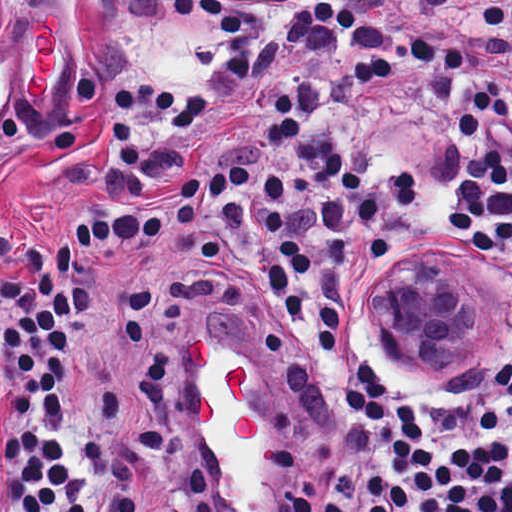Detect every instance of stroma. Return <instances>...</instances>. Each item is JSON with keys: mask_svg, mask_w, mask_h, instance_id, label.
Wrapping results in <instances>:
<instances>
[{"mask_svg": "<svg viewBox=\"0 0 512 512\" xmlns=\"http://www.w3.org/2000/svg\"><path fill=\"white\" fill-rule=\"evenodd\" d=\"M190 0H0V270L28 235H65L101 198L115 81L142 78L181 30ZM63 19L62 62L39 101L23 93L26 21ZM437 264L456 269L448 256ZM184 430L208 476L212 512H286L265 427V387L238 361L191 362ZM9 387L0 369V438Z\"/></svg>", "mask_w": 512, "mask_h": 512, "instance_id": "35a3bbf8", "label": "stroma"}]
</instances>
